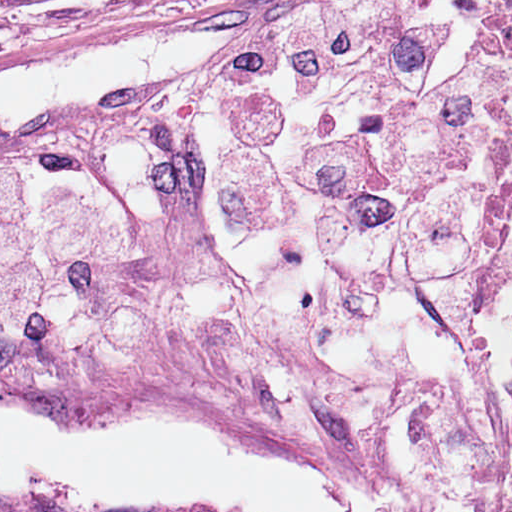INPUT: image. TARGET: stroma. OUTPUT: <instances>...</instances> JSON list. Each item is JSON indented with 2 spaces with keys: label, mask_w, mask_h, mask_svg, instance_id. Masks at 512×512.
I'll return each mask as SVG.
<instances>
[{
  "label": "stroma",
  "mask_w": 512,
  "mask_h": 512,
  "mask_svg": "<svg viewBox=\"0 0 512 512\" xmlns=\"http://www.w3.org/2000/svg\"><path fill=\"white\" fill-rule=\"evenodd\" d=\"M350 1L69 0L4 4L0 5V71L37 53L104 36L238 23L221 34L185 73L129 99L133 100L212 74L232 64L250 42L286 22L332 11ZM470 1L498 23L501 17L512 15V0ZM83 119L39 128L0 145V151L40 137L65 134ZM511 371L512 296L503 411L487 454L469 458L473 470L471 497L482 512H512ZM0 409L38 411L79 426L124 423L165 411L191 415L268 465L331 472L374 483L393 481L399 450L380 442L319 437L185 383L117 367L0 360Z\"/></svg>",
  "instance_id": "obj_1"
}]
</instances>
